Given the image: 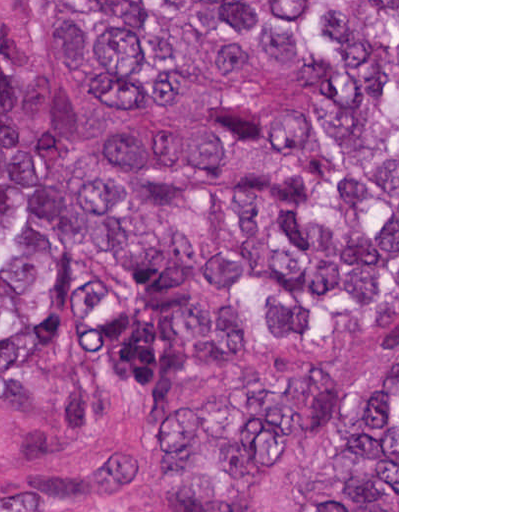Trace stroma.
<instances>
[{"mask_svg":"<svg viewBox=\"0 0 512 512\" xmlns=\"http://www.w3.org/2000/svg\"><path fill=\"white\" fill-rule=\"evenodd\" d=\"M62 28V0H0V58L42 48L81 107V128L118 206L149 213L168 224L185 242L206 277V239L184 217L153 213L119 191L101 164L93 99L79 72L62 56L54 37ZM226 299L240 304L228 293ZM397 352V512H399V0H397V329L355 340L349 345L302 355H274L264 339L262 353L235 358L194 392L168 400H150L98 431L65 428L58 411L56 381L44 373L29 400L0 403V502L48 486L83 468L126 457H143L154 472L152 512H183L165 469L162 436L165 416L226 391L250 367L281 361L316 364L328 373L342 404H357L375 374ZM121 417V418H120ZM120 418V419H119ZM119 419V420H118ZM330 438L318 439L294 455L287 469L241 512H280L287 499L303 490L316 471Z\"/></svg>","mask_w":512,"mask_h":512,"instance_id":"stroma-1","label":"stroma"}]
</instances>
